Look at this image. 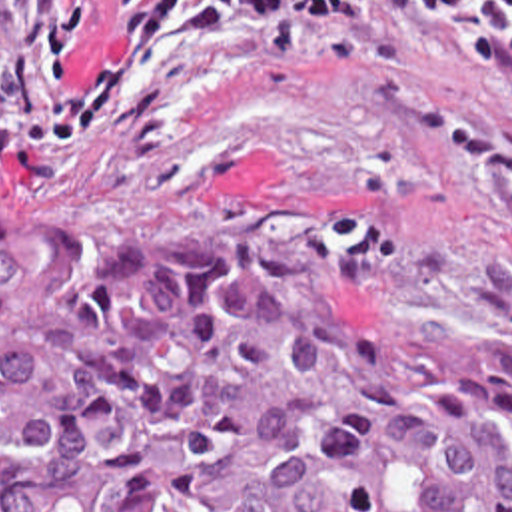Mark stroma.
<instances>
[{
    "label": "stroma",
    "mask_w": 512,
    "mask_h": 512,
    "mask_svg": "<svg viewBox=\"0 0 512 512\" xmlns=\"http://www.w3.org/2000/svg\"><path fill=\"white\" fill-rule=\"evenodd\" d=\"M63 2L0 0V200L512 351V0H350L275 66L235 28H173L91 142H29L113 32L101 0L63 72Z\"/></svg>",
    "instance_id": "35a3bbf8"
}]
</instances>
